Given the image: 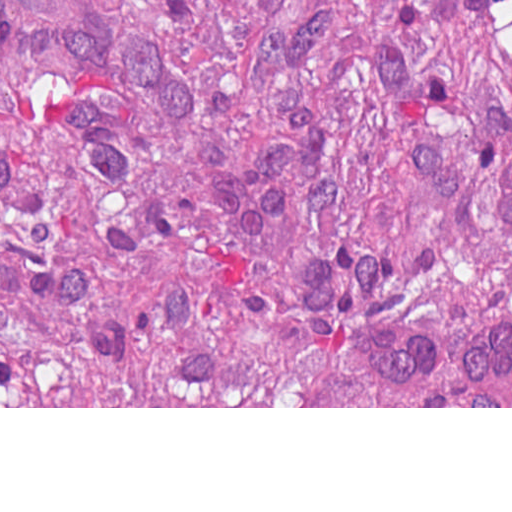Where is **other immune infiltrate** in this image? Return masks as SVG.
Returning a JSON list of instances; mask_svg holds the SVG:
<instances>
[{"label":"other immune infiltrate","instance_id":"bc1004c8","mask_svg":"<svg viewBox=\"0 0 512 512\" xmlns=\"http://www.w3.org/2000/svg\"><path fill=\"white\" fill-rule=\"evenodd\" d=\"M495 219L499 237L512 250V162L495 195ZM347 342L368 376L401 395L450 406H512V311L507 310V319L463 338L392 322H353Z\"/></svg>","mask_w":512,"mask_h":512}]
</instances>
